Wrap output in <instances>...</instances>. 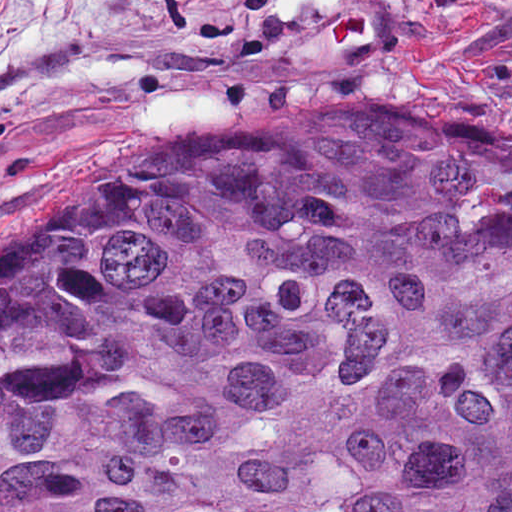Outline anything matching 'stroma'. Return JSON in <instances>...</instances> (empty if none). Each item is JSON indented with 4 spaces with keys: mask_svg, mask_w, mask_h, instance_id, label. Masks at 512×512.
<instances>
[{
    "mask_svg": "<svg viewBox=\"0 0 512 512\" xmlns=\"http://www.w3.org/2000/svg\"><path fill=\"white\" fill-rule=\"evenodd\" d=\"M371 97L512 145V0H0V280L210 127Z\"/></svg>",
    "mask_w": 512,
    "mask_h": 512,
    "instance_id": "stroma-1",
    "label": "stroma"
}]
</instances>
